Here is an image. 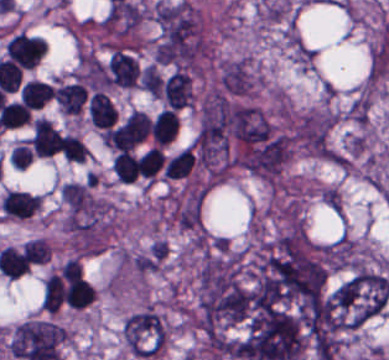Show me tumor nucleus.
<instances>
[{
    "mask_svg": "<svg viewBox=\"0 0 389 360\" xmlns=\"http://www.w3.org/2000/svg\"><path fill=\"white\" fill-rule=\"evenodd\" d=\"M120 338L134 357H156L165 345V322L154 308L144 306L123 319Z\"/></svg>",
    "mask_w": 389,
    "mask_h": 360,
    "instance_id": "2f306a5c",
    "label": "tumor nucleus"
},
{
    "mask_svg": "<svg viewBox=\"0 0 389 360\" xmlns=\"http://www.w3.org/2000/svg\"><path fill=\"white\" fill-rule=\"evenodd\" d=\"M139 88L151 98H160L161 80L150 63L141 70Z\"/></svg>",
    "mask_w": 389,
    "mask_h": 360,
    "instance_id": "8643909e",
    "label": "tumor nucleus"
}]
</instances>
